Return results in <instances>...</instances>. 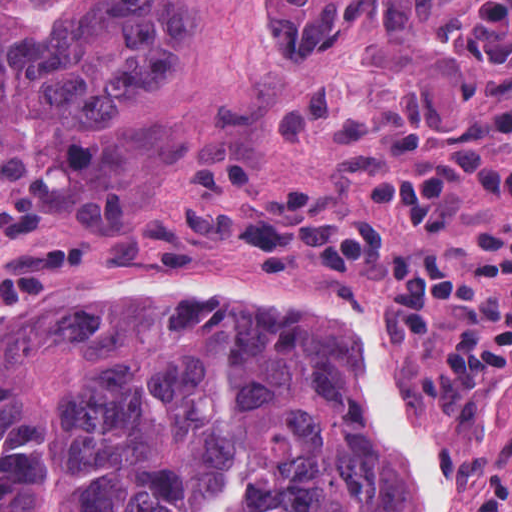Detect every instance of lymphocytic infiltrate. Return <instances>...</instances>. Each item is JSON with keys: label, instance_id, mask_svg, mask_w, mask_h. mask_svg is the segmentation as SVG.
I'll return each mask as SVG.
<instances>
[{"label": "lymphocytic infiltrate", "instance_id": "f902f5d3", "mask_svg": "<svg viewBox=\"0 0 512 512\" xmlns=\"http://www.w3.org/2000/svg\"><path fill=\"white\" fill-rule=\"evenodd\" d=\"M252 112L280 133L336 138V170L365 193L369 214L392 215L428 241H449L467 187L483 208L512 215V103L448 102L434 76L411 67L355 96L309 79L258 83ZM221 200L228 248L244 271L291 278L337 270L373 284L387 342L442 363L462 388L512 385V222L486 221L472 261L398 242L369 220L325 216L311 191L256 190L225 170Z\"/></svg>", "mask_w": 512, "mask_h": 512}]
</instances>
